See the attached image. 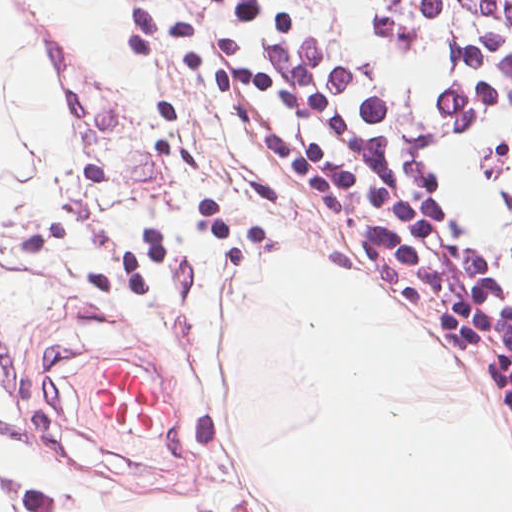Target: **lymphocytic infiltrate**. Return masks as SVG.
<instances>
[{
	"instance_id": "lymphocytic-infiltrate-1",
	"label": "lymphocytic infiltrate",
	"mask_w": 512,
	"mask_h": 512,
	"mask_svg": "<svg viewBox=\"0 0 512 512\" xmlns=\"http://www.w3.org/2000/svg\"><path fill=\"white\" fill-rule=\"evenodd\" d=\"M484 326L512 425V0H278Z\"/></svg>"
}]
</instances>
